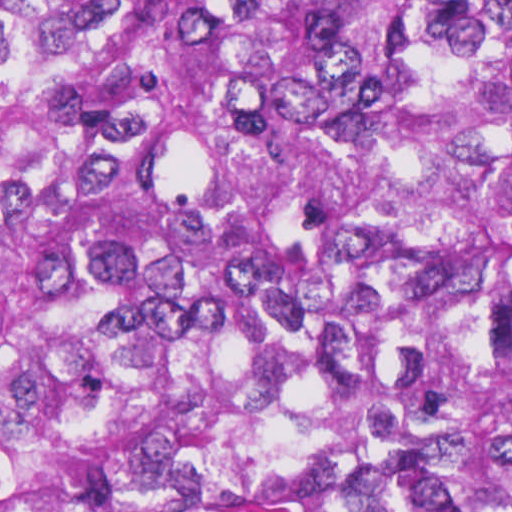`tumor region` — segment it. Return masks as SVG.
I'll return each mask as SVG.
<instances>
[{
	"mask_svg": "<svg viewBox=\"0 0 512 512\" xmlns=\"http://www.w3.org/2000/svg\"><path fill=\"white\" fill-rule=\"evenodd\" d=\"M0 512H512V0H0Z\"/></svg>",
	"mask_w": 512,
	"mask_h": 512,
	"instance_id": "e687c5a6",
	"label": "tumor region"
}]
</instances>
